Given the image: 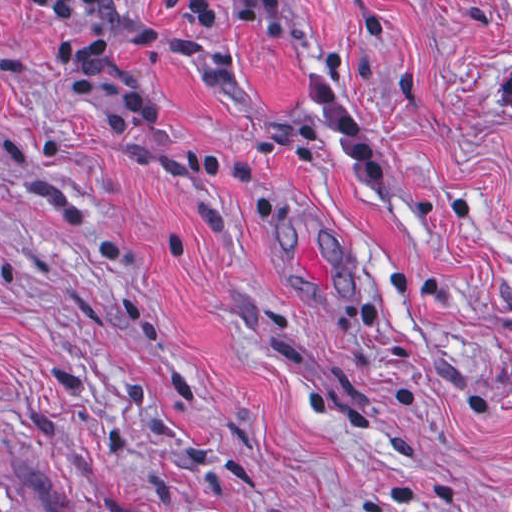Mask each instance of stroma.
Here are the masks:
<instances>
[{
    "label": "stroma",
    "instance_id": "stroma-1",
    "mask_svg": "<svg viewBox=\"0 0 512 512\" xmlns=\"http://www.w3.org/2000/svg\"><path fill=\"white\" fill-rule=\"evenodd\" d=\"M211 1L0 0V512H512V0Z\"/></svg>",
    "mask_w": 512,
    "mask_h": 512
}]
</instances>
